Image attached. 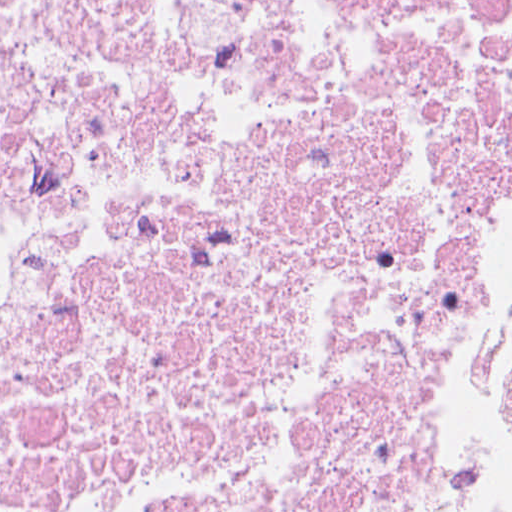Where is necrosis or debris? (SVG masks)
<instances>
[{"label":"necrosis or debris","mask_w":512,"mask_h":512,"mask_svg":"<svg viewBox=\"0 0 512 512\" xmlns=\"http://www.w3.org/2000/svg\"><path fill=\"white\" fill-rule=\"evenodd\" d=\"M469 5L0 0V512H411Z\"/></svg>","instance_id":"4bbe7bcc"}]
</instances>
